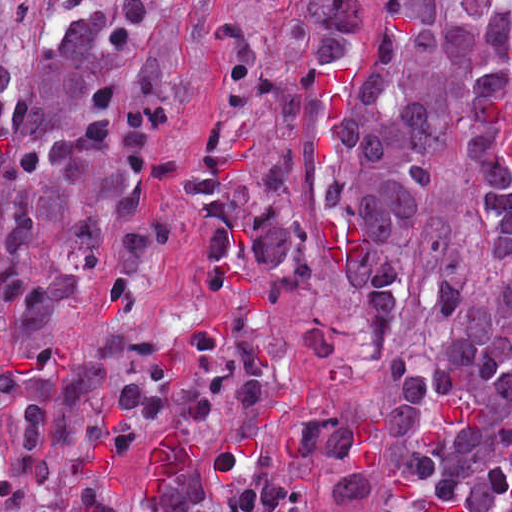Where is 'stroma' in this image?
<instances>
[{
    "label": "stroma",
    "mask_w": 512,
    "mask_h": 512,
    "mask_svg": "<svg viewBox=\"0 0 512 512\" xmlns=\"http://www.w3.org/2000/svg\"><path fill=\"white\" fill-rule=\"evenodd\" d=\"M51 1L19 0L2 16L0 34L10 83H19L31 62ZM239 1L184 0L187 82L171 105L164 127V146L178 152L181 168L157 191L161 257L147 285L131 292L128 306L87 289L47 344L34 354H18L0 323V368L51 365L110 329H159L197 312L206 297V277L185 222V164L195 148L215 137L277 138L299 160L310 218V253L292 303V353L283 410L295 418L321 394L347 398L363 409L378 452L382 387L375 335L358 302L365 249L352 218L337 208L327 192L331 140L374 29L349 58L331 118L315 125L286 127L244 105L228 103L207 79V46ZM501 160L512 183V139ZM368 512H382V485L381 498Z\"/></svg>",
    "instance_id": "stroma-1"
}]
</instances>
